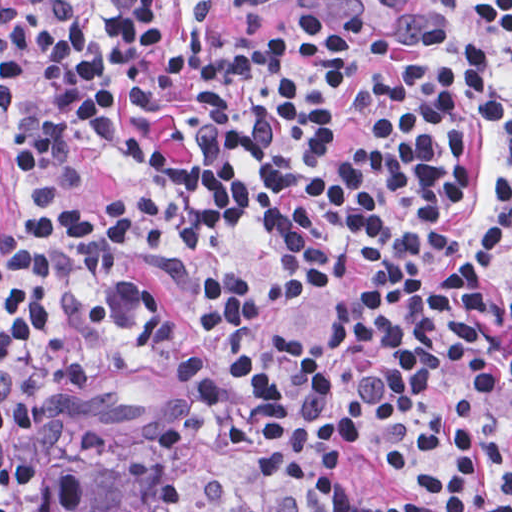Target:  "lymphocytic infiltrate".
I'll list each match as a JSON object with an SVG mask.
<instances>
[{"label": "lymphocytic infiltrate", "mask_w": 512, "mask_h": 512, "mask_svg": "<svg viewBox=\"0 0 512 512\" xmlns=\"http://www.w3.org/2000/svg\"><path fill=\"white\" fill-rule=\"evenodd\" d=\"M213 1L0 0V512L77 510L81 473L27 441L69 417L98 449L89 384L136 342L180 388L158 443L245 456L246 512H512L503 51L447 64L326 0L228 33ZM468 1L511 45L512 0ZM508 248L510 300L483 270ZM129 256L196 264L187 323ZM279 296L332 309L319 358L249 345Z\"/></svg>", "instance_id": "f902f5d3"}]
</instances>
